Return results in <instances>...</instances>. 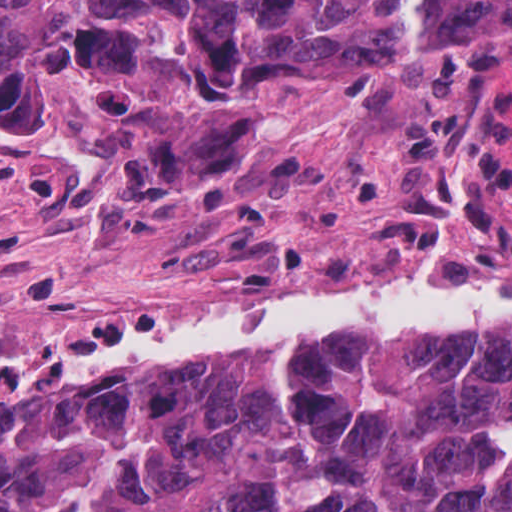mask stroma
Segmentation results:
<instances>
[{"instance_id": "stroma-1", "label": "stroma", "mask_w": 512, "mask_h": 512, "mask_svg": "<svg viewBox=\"0 0 512 512\" xmlns=\"http://www.w3.org/2000/svg\"><path fill=\"white\" fill-rule=\"evenodd\" d=\"M467 89L505 127L512 150V57L485 47L406 57L369 80L253 91L231 112L219 147L186 159L139 112L34 123L0 111V310L91 294L148 304L243 232L261 196L365 142L403 134L440 98ZM422 277L512 286V275ZM395 285L288 308L229 298L69 348L0 357V384L65 371L113 339L201 314L300 310Z\"/></svg>"}]
</instances>
